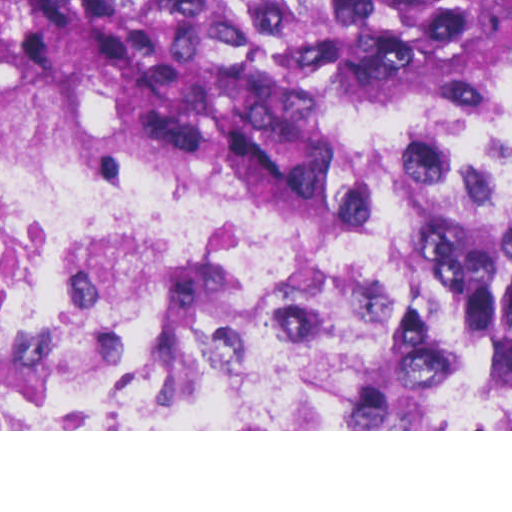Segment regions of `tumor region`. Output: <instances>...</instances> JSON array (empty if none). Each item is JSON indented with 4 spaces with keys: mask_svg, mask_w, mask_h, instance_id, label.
<instances>
[{
    "mask_svg": "<svg viewBox=\"0 0 512 512\" xmlns=\"http://www.w3.org/2000/svg\"><path fill=\"white\" fill-rule=\"evenodd\" d=\"M466 66L512 69V0H0V160L340 188L347 100Z\"/></svg>",
    "mask_w": 512,
    "mask_h": 512,
    "instance_id": "1",
    "label": "tumor region"
}]
</instances>
